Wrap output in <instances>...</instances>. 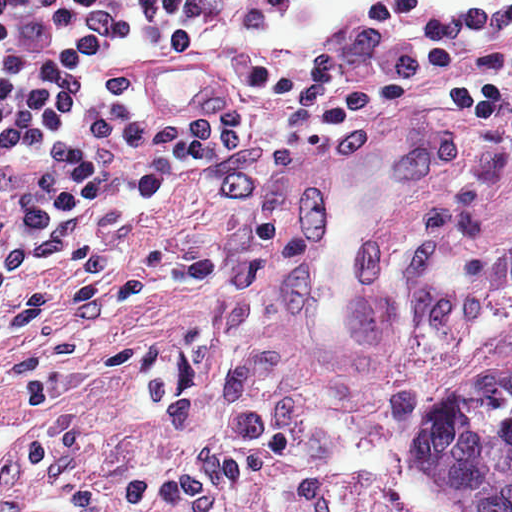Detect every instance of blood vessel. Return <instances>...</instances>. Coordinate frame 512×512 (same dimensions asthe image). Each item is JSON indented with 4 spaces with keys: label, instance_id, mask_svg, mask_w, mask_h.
Returning a JSON list of instances; mask_svg holds the SVG:
<instances>
[{
    "label": "blood vessel",
    "instance_id": "blood-vessel-1",
    "mask_svg": "<svg viewBox=\"0 0 512 512\" xmlns=\"http://www.w3.org/2000/svg\"><path fill=\"white\" fill-rule=\"evenodd\" d=\"M120 90L148 114H213L232 96V75L198 52L123 49Z\"/></svg>",
    "mask_w": 512,
    "mask_h": 512
}]
</instances>
